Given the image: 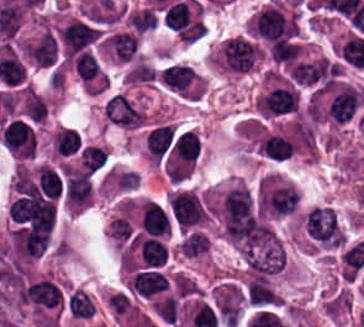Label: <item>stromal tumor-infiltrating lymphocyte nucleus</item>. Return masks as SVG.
Instances as JSON below:
<instances>
[{
  "mask_svg": "<svg viewBox=\"0 0 364 327\" xmlns=\"http://www.w3.org/2000/svg\"><path fill=\"white\" fill-rule=\"evenodd\" d=\"M0 137L15 156H34L36 152V134L21 118L7 122Z\"/></svg>",
  "mask_w": 364,
  "mask_h": 327,
  "instance_id": "obj_11",
  "label": "stromal tumor-infiltrating lymphocyte nucleus"
},
{
  "mask_svg": "<svg viewBox=\"0 0 364 327\" xmlns=\"http://www.w3.org/2000/svg\"><path fill=\"white\" fill-rule=\"evenodd\" d=\"M67 314L77 320H89L94 316L95 309L92 298L81 288H72L64 296Z\"/></svg>",
  "mask_w": 364,
  "mask_h": 327,
  "instance_id": "obj_12",
  "label": "stromal tumor-infiltrating lymphocyte nucleus"
},
{
  "mask_svg": "<svg viewBox=\"0 0 364 327\" xmlns=\"http://www.w3.org/2000/svg\"><path fill=\"white\" fill-rule=\"evenodd\" d=\"M101 48L112 62L128 64L138 58V32L127 29L106 32L101 37Z\"/></svg>",
  "mask_w": 364,
  "mask_h": 327,
  "instance_id": "obj_8",
  "label": "stromal tumor-infiltrating lymphocyte nucleus"
},
{
  "mask_svg": "<svg viewBox=\"0 0 364 327\" xmlns=\"http://www.w3.org/2000/svg\"><path fill=\"white\" fill-rule=\"evenodd\" d=\"M260 57L259 47L245 35L230 36L223 40L214 59L227 73L244 74Z\"/></svg>",
  "mask_w": 364,
  "mask_h": 327,
  "instance_id": "obj_5",
  "label": "stromal tumor-infiltrating lymphocyte nucleus"
},
{
  "mask_svg": "<svg viewBox=\"0 0 364 327\" xmlns=\"http://www.w3.org/2000/svg\"><path fill=\"white\" fill-rule=\"evenodd\" d=\"M297 193L278 181L262 178L258 184V210L284 214L291 211L297 202Z\"/></svg>",
  "mask_w": 364,
  "mask_h": 327,
  "instance_id": "obj_6",
  "label": "stromal tumor-infiltrating lymphocyte nucleus"
},
{
  "mask_svg": "<svg viewBox=\"0 0 364 327\" xmlns=\"http://www.w3.org/2000/svg\"><path fill=\"white\" fill-rule=\"evenodd\" d=\"M169 258V247L163 236L153 232H133L122 252L124 271L160 267Z\"/></svg>",
  "mask_w": 364,
  "mask_h": 327,
  "instance_id": "obj_2",
  "label": "stromal tumor-infiltrating lymphocyte nucleus"
},
{
  "mask_svg": "<svg viewBox=\"0 0 364 327\" xmlns=\"http://www.w3.org/2000/svg\"><path fill=\"white\" fill-rule=\"evenodd\" d=\"M162 18L165 26L180 32L191 22L188 5L182 0L168 6Z\"/></svg>",
  "mask_w": 364,
  "mask_h": 327,
  "instance_id": "obj_17",
  "label": "stromal tumor-infiltrating lymphocyte nucleus"
},
{
  "mask_svg": "<svg viewBox=\"0 0 364 327\" xmlns=\"http://www.w3.org/2000/svg\"><path fill=\"white\" fill-rule=\"evenodd\" d=\"M363 100L360 89L338 81L331 85L320 103L322 118L343 125L359 114Z\"/></svg>",
  "mask_w": 364,
  "mask_h": 327,
  "instance_id": "obj_4",
  "label": "stromal tumor-infiltrating lymphocyte nucleus"
},
{
  "mask_svg": "<svg viewBox=\"0 0 364 327\" xmlns=\"http://www.w3.org/2000/svg\"><path fill=\"white\" fill-rule=\"evenodd\" d=\"M299 223L312 244L333 251L344 246L343 228L329 205H316L304 211Z\"/></svg>",
  "mask_w": 364,
  "mask_h": 327,
  "instance_id": "obj_1",
  "label": "stromal tumor-infiltrating lymphocyte nucleus"
},
{
  "mask_svg": "<svg viewBox=\"0 0 364 327\" xmlns=\"http://www.w3.org/2000/svg\"><path fill=\"white\" fill-rule=\"evenodd\" d=\"M106 307L111 315L119 318H127L138 312L134 298L120 289L108 295Z\"/></svg>",
  "mask_w": 364,
  "mask_h": 327,
  "instance_id": "obj_16",
  "label": "stromal tumor-infiltrating lymphocyte nucleus"
},
{
  "mask_svg": "<svg viewBox=\"0 0 364 327\" xmlns=\"http://www.w3.org/2000/svg\"><path fill=\"white\" fill-rule=\"evenodd\" d=\"M165 205L170 225L178 230L198 227L208 216V208L200 194L184 188L174 189L167 196Z\"/></svg>",
  "mask_w": 364,
  "mask_h": 327,
  "instance_id": "obj_3",
  "label": "stromal tumor-infiltrating lymphocyte nucleus"
},
{
  "mask_svg": "<svg viewBox=\"0 0 364 327\" xmlns=\"http://www.w3.org/2000/svg\"><path fill=\"white\" fill-rule=\"evenodd\" d=\"M239 294L244 303L254 310H270L281 304L280 295L268 276L249 273Z\"/></svg>",
  "mask_w": 364,
  "mask_h": 327,
  "instance_id": "obj_7",
  "label": "stromal tumor-infiltrating lymphocyte nucleus"
},
{
  "mask_svg": "<svg viewBox=\"0 0 364 327\" xmlns=\"http://www.w3.org/2000/svg\"><path fill=\"white\" fill-rule=\"evenodd\" d=\"M157 22V11L147 5H140L125 11L123 26L136 32H146Z\"/></svg>",
  "mask_w": 364,
  "mask_h": 327,
  "instance_id": "obj_14",
  "label": "stromal tumor-infiltrating lymphocyte nucleus"
},
{
  "mask_svg": "<svg viewBox=\"0 0 364 327\" xmlns=\"http://www.w3.org/2000/svg\"><path fill=\"white\" fill-rule=\"evenodd\" d=\"M107 160V148L99 142H85L77 157L78 165L94 173L106 167Z\"/></svg>",
  "mask_w": 364,
  "mask_h": 327,
  "instance_id": "obj_13",
  "label": "stromal tumor-infiltrating lymphocyte nucleus"
},
{
  "mask_svg": "<svg viewBox=\"0 0 364 327\" xmlns=\"http://www.w3.org/2000/svg\"><path fill=\"white\" fill-rule=\"evenodd\" d=\"M101 115L110 125L123 130H137L144 122L142 106L123 93Z\"/></svg>",
  "mask_w": 364,
  "mask_h": 327,
  "instance_id": "obj_10",
  "label": "stromal tumor-infiltrating lymphocyte nucleus"
},
{
  "mask_svg": "<svg viewBox=\"0 0 364 327\" xmlns=\"http://www.w3.org/2000/svg\"><path fill=\"white\" fill-rule=\"evenodd\" d=\"M294 145L281 134H268L258 142L260 153L277 160H282L292 154Z\"/></svg>",
  "mask_w": 364,
  "mask_h": 327,
  "instance_id": "obj_15",
  "label": "stromal tumor-infiltrating lymphocyte nucleus"
},
{
  "mask_svg": "<svg viewBox=\"0 0 364 327\" xmlns=\"http://www.w3.org/2000/svg\"><path fill=\"white\" fill-rule=\"evenodd\" d=\"M161 85L184 98H199L200 79L187 64L169 63L162 69Z\"/></svg>",
  "mask_w": 364,
  "mask_h": 327,
  "instance_id": "obj_9",
  "label": "stromal tumor-infiltrating lymphocyte nucleus"
}]
</instances>
